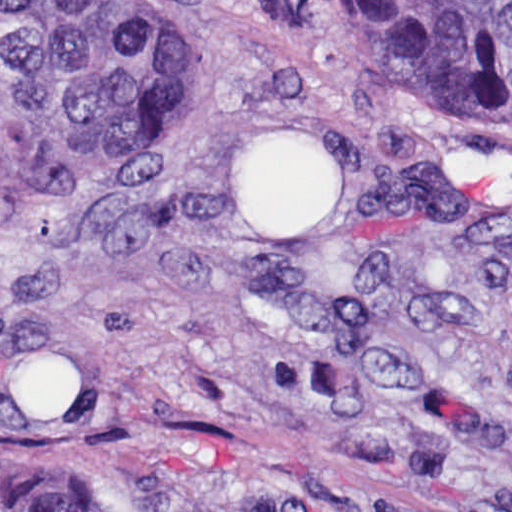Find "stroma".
<instances>
[{
	"instance_id": "obj_1",
	"label": "stroma",
	"mask_w": 512,
	"mask_h": 512,
	"mask_svg": "<svg viewBox=\"0 0 512 512\" xmlns=\"http://www.w3.org/2000/svg\"><path fill=\"white\" fill-rule=\"evenodd\" d=\"M166 72L1 189V491L150 463L308 512H512V129L317 0H117Z\"/></svg>"
}]
</instances>
